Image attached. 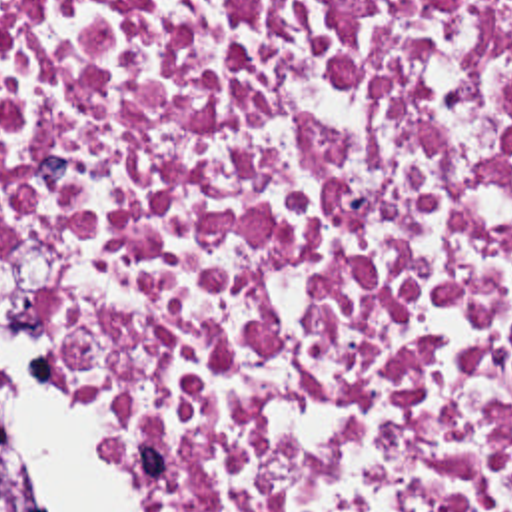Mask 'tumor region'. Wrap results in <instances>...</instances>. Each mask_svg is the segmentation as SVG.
Returning <instances> with one entry per match:
<instances>
[{
    "label": "tumor region",
    "instance_id": "obj_1",
    "mask_svg": "<svg viewBox=\"0 0 512 512\" xmlns=\"http://www.w3.org/2000/svg\"><path fill=\"white\" fill-rule=\"evenodd\" d=\"M0 512H40L24 484L12 438L0 422Z\"/></svg>",
    "mask_w": 512,
    "mask_h": 512
}]
</instances>
